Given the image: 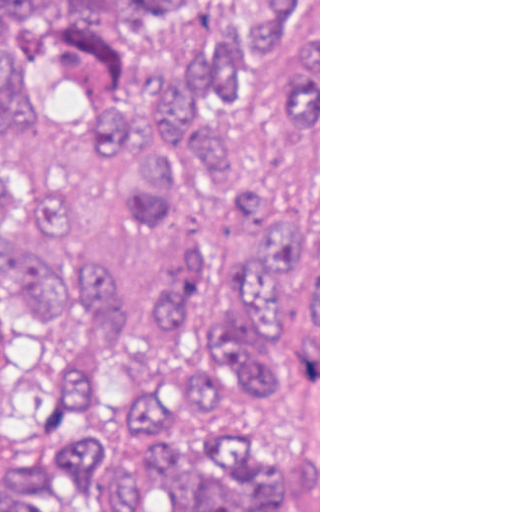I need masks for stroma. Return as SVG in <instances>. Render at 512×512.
<instances>
[{
  "mask_svg": "<svg viewBox=\"0 0 512 512\" xmlns=\"http://www.w3.org/2000/svg\"><path fill=\"white\" fill-rule=\"evenodd\" d=\"M147 372L136 384L90 379L87 398L73 416L58 400L63 368L42 329L29 324L0 289V474L61 448L65 436H104L134 451V410ZM239 415L262 439L272 464L300 448L306 414L293 393L259 390L237 375H222L218 400L202 407L188 401L156 430L176 451L190 476L197 465L209 418ZM318 512H320V0H318Z\"/></svg>",
  "mask_w": 512,
  "mask_h": 512,
  "instance_id": "stroma-1",
  "label": "stroma"
}]
</instances>
